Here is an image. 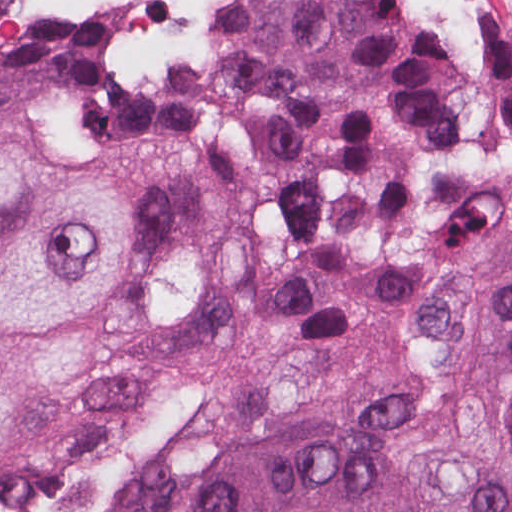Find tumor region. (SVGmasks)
Segmentation results:
<instances>
[{"mask_svg": "<svg viewBox=\"0 0 512 512\" xmlns=\"http://www.w3.org/2000/svg\"><path fill=\"white\" fill-rule=\"evenodd\" d=\"M113 39L114 14L1 34L0 105L63 129L217 144L262 230L297 208L396 224L451 158H512V40L441 47L385 0H246L211 57L160 87L104 71ZM222 207L180 149L56 147L0 113V445L22 391L84 368L78 332L132 270ZM490 352L508 422L455 482L417 487L361 436H287L225 463L180 512H512V249Z\"/></svg>", "mask_w": 512, "mask_h": 512, "instance_id": "tumor-region-1", "label": "tumor region"}]
</instances>
